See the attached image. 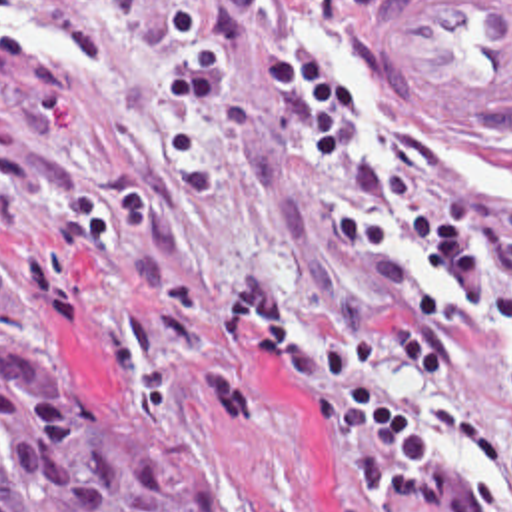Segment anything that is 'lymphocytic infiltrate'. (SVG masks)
<instances>
[{
    "mask_svg": "<svg viewBox=\"0 0 512 512\" xmlns=\"http://www.w3.org/2000/svg\"><path fill=\"white\" fill-rule=\"evenodd\" d=\"M284 26L260 36L264 86L328 170L306 194L326 246L360 295L362 341L304 323L288 285L238 283L212 313V417L260 429L250 395V323L312 399L334 459V512H512V461L410 381L437 377L463 325L512 335V208L471 160L422 134L358 144L348 88L304 58V26L332 0H282ZM402 254L431 260L445 287Z\"/></svg>",
    "mask_w": 512,
    "mask_h": 512,
    "instance_id": "1",
    "label": "lymphocytic infiltrate"
}]
</instances>
